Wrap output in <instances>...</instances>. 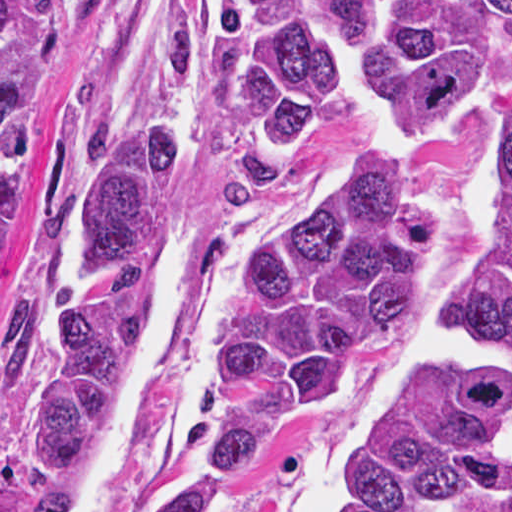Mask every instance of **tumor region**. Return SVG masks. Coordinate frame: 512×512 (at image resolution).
I'll return each mask as SVG.
<instances>
[{
	"label": "tumor region",
	"mask_w": 512,
	"mask_h": 512,
	"mask_svg": "<svg viewBox=\"0 0 512 512\" xmlns=\"http://www.w3.org/2000/svg\"><path fill=\"white\" fill-rule=\"evenodd\" d=\"M62 1L0 0V376L34 326L53 334L26 444L45 477L71 480L129 278L175 229L188 120L179 102H111L74 142L46 234L11 211L59 90ZM358 79L398 140L312 186L253 249L217 330L222 421L164 512H236L249 467L345 398L447 231L420 151L486 110L500 117L494 212L439 315L478 333L479 358L420 370L375 405L342 512H436L512 482V0H224L208 102L225 193L274 191Z\"/></svg>",
	"instance_id": "tumor-region-1"
}]
</instances>
